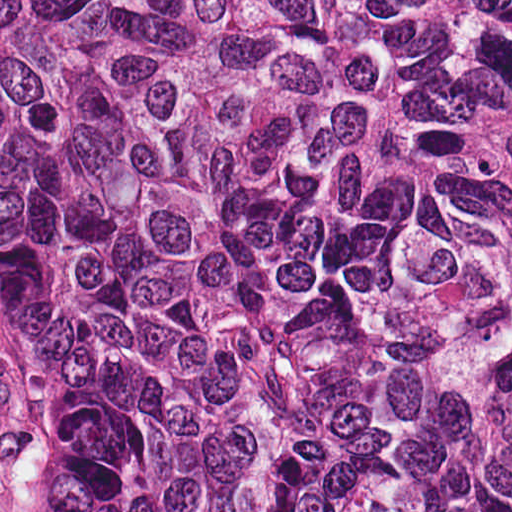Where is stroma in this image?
<instances>
[{
	"instance_id": "obj_1",
	"label": "stroma",
	"mask_w": 512,
	"mask_h": 512,
	"mask_svg": "<svg viewBox=\"0 0 512 512\" xmlns=\"http://www.w3.org/2000/svg\"><path fill=\"white\" fill-rule=\"evenodd\" d=\"M0 512H52V414L38 373L1 326Z\"/></svg>"
}]
</instances>
